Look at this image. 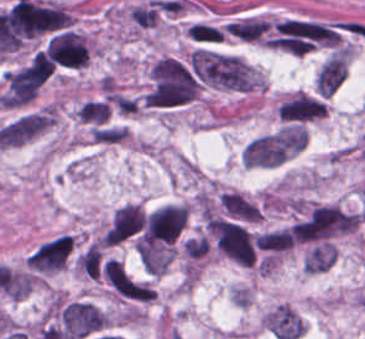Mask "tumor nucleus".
<instances>
[{
  "instance_id": "tumor-nucleus-1",
  "label": "tumor nucleus",
  "mask_w": 365,
  "mask_h": 339,
  "mask_svg": "<svg viewBox=\"0 0 365 339\" xmlns=\"http://www.w3.org/2000/svg\"><path fill=\"white\" fill-rule=\"evenodd\" d=\"M199 92L200 81L190 62L162 56L151 66L143 104L178 107L194 101Z\"/></svg>"
},
{
  "instance_id": "tumor-nucleus-2",
  "label": "tumor nucleus",
  "mask_w": 365,
  "mask_h": 339,
  "mask_svg": "<svg viewBox=\"0 0 365 339\" xmlns=\"http://www.w3.org/2000/svg\"><path fill=\"white\" fill-rule=\"evenodd\" d=\"M190 61L197 75L209 85L231 90H252L250 66L237 55L193 53Z\"/></svg>"
},
{
  "instance_id": "tumor-nucleus-3",
  "label": "tumor nucleus",
  "mask_w": 365,
  "mask_h": 339,
  "mask_svg": "<svg viewBox=\"0 0 365 339\" xmlns=\"http://www.w3.org/2000/svg\"><path fill=\"white\" fill-rule=\"evenodd\" d=\"M53 72L52 66L36 56L8 71L3 81V104L31 101Z\"/></svg>"
},
{
  "instance_id": "tumor-nucleus-4",
  "label": "tumor nucleus",
  "mask_w": 365,
  "mask_h": 339,
  "mask_svg": "<svg viewBox=\"0 0 365 339\" xmlns=\"http://www.w3.org/2000/svg\"><path fill=\"white\" fill-rule=\"evenodd\" d=\"M103 311L82 299L61 301L54 313V326L77 339H87L105 329Z\"/></svg>"
},
{
  "instance_id": "tumor-nucleus-5",
  "label": "tumor nucleus",
  "mask_w": 365,
  "mask_h": 339,
  "mask_svg": "<svg viewBox=\"0 0 365 339\" xmlns=\"http://www.w3.org/2000/svg\"><path fill=\"white\" fill-rule=\"evenodd\" d=\"M210 227L224 253L245 266H253L256 253L249 231L236 222L220 219H213Z\"/></svg>"
},
{
  "instance_id": "tumor-nucleus-6",
  "label": "tumor nucleus",
  "mask_w": 365,
  "mask_h": 339,
  "mask_svg": "<svg viewBox=\"0 0 365 339\" xmlns=\"http://www.w3.org/2000/svg\"><path fill=\"white\" fill-rule=\"evenodd\" d=\"M187 217L183 205H163L148 216L142 238L152 246L169 245L179 236Z\"/></svg>"
},
{
  "instance_id": "tumor-nucleus-7",
  "label": "tumor nucleus",
  "mask_w": 365,
  "mask_h": 339,
  "mask_svg": "<svg viewBox=\"0 0 365 339\" xmlns=\"http://www.w3.org/2000/svg\"><path fill=\"white\" fill-rule=\"evenodd\" d=\"M74 239L60 234L39 245L29 256L27 264L38 274L60 271L72 253Z\"/></svg>"
},
{
  "instance_id": "tumor-nucleus-8",
  "label": "tumor nucleus",
  "mask_w": 365,
  "mask_h": 339,
  "mask_svg": "<svg viewBox=\"0 0 365 339\" xmlns=\"http://www.w3.org/2000/svg\"><path fill=\"white\" fill-rule=\"evenodd\" d=\"M288 152L277 133L255 137L245 148L242 163L249 166H273L287 159Z\"/></svg>"
},
{
  "instance_id": "tumor-nucleus-9",
  "label": "tumor nucleus",
  "mask_w": 365,
  "mask_h": 339,
  "mask_svg": "<svg viewBox=\"0 0 365 339\" xmlns=\"http://www.w3.org/2000/svg\"><path fill=\"white\" fill-rule=\"evenodd\" d=\"M145 218L140 206L126 203L116 210L106 228L105 245H118L143 227Z\"/></svg>"
},
{
  "instance_id": "tumor-nucleus-10",
  "label": "tumor nucleus",
  "mask_w": 365,
  "mask_h": 339,
  "mask_svg": "<svg viewBox=\"0 0 365 339\" xmlns=\"http://www.w3.org/2000/svg\"><path fill=\"white\" fill-rule=\"evenodd\" d=\"M263 323L276 339H296L302 334V318L286 304H278L269 311Z\"/></svg>"
},
{
  "instance_id": "tumor-nucleus-11",
  "label": "tumor nucleus",
  "mask_w": 365,
  "mask_h": 339,
  "mask_svg": "<svg viewBox=\"0 0 365 339\" xmlns=\"http://www.w3.org/2000/svg\"><path fill=\"white\" fill-rule=\"evenodd\" d=\"M348 74V55L338 51L331 56L318 75V88L321 94L331 96L344 82Z\"/></svg>"
},
{
  "instance_id": "tumor-nucleus-12",
  "label": "tumor nucleus",
  "mask_w": 365,
  "mask_h": 339,
  "mask_svg": "<svg viewBox=\"0 0 365 339\" xmlns=\"http://www.w3.org/2000/svg\"><path fill=\"white\" fill-rule=\"evenodd\" d=\"M319 96L295 94L282 118L288 124L309 122L318 118Z\"/></svg>"
},
{
  "instance_id": "tumor-nucleus-13",
  "label": "tumor nucleus",
  "mask_w": 365,
  "mask_h": 339,
  "mask_svg": "<svg viewBox=\"0 0 365 339\" xmlns=\"http://www.w3.org/2000/svg\"><path fill=\"white\" fill-rule=\"evenodd\" d=\"M307 129L300 124L282 127L275 135L274 140L284 153L291 154L305 147Z\"/></svg>"
},
{
  "instance_id": "tumor-nucleus-14",
  "label": "tumor nucleus",
  "mask_w": 365,
  "mask_h": 339,
  "mask_svg": "<svg viewBox=\"0 0 365 339\" xmlns=\"http://www.w3.org/2000/svg\"><path fill=\"white\" fill-rule=\"evenodd\" d=\"M225 28L242 40H258L269 25L266 19L245 18L230 22Z\"/></svg>"
},
{
  "instance_id": "tumor-nucleus-15",
  "label": "tumor nucleus",
  "mask_w": 365,
  "mask_h": 339,
  "mask_svg": "<svg viewBox=\"0 0 365 339\" xmlns=\"http://www.w3.org/2000/svg\"><path fill=\"white\" fill-rule=\"evenodd\" d=\"M77 116L86 123H106L111 110L109 102L102 98H95L84 102L76 110Z\"/></svg>"
},
{
  "instance_id": "tumor-nucleus-16",
  "label": "tumor nucleus",
  "mask_w": 365,
  "mask_h": 339,
  "mask_svg": "<svg viewBox=\"0 0 365 339\" xmlns=\"http://www.w3.org/2000/svg\"><path fill=\"white\" fill-rule=\"evenodd\" d=\"M255 245L273 251H286L293 246V239L287 230L263 232L255 239Z\"/></svg>"
},
{
  "instance_id": "tumor-nucleus-17",
  "label": "tumor nucleus",
  "mask_w": 365,
  "mask_h": 339,
  "mask_svg": "<svg viewBox=\"0 0 365 339\" xmlns=\"http://www.w3.org/2000/svg\"><path fill=\"white\" fill-rule=\"evenodd\" d=\"M132 24L141 28L151 27L158 19L157 4L146 1L130 8Z\"/></svg>"
},
{
  "instance_id": "tumor-nucleus-18",
  "label": "tumor nucleus",
  "mask_w": 365,
  "mask_h": 339,
  "mask_svg": "<svg viewBox=\"0 0 365 339\" xmlns=\"http://www.w3.org/2000/svg\"><path fill=\"white\" fill-rule=\"evenodd\" d=\"M190 37L197 41H221L223 32L221 29L205 23H196L188 27Z\"/></svg>"
}]
</instances>
